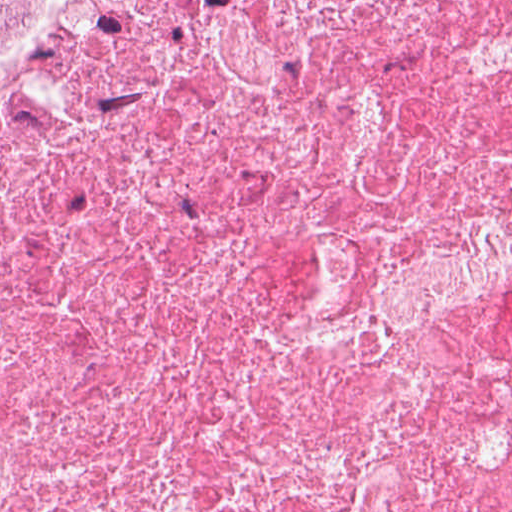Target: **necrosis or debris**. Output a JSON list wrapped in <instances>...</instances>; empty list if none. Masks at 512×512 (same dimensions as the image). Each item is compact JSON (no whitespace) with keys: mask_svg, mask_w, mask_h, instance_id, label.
Returning a JSON list of instances; mask_svg holds the SVG:
<instances>
[{"mask_svg":"<svg viewBox=\"0 0 512 512\" xmlns=\"http://www.w3.org/2000/svg\"><path fill=\"white\" fill-rule=\"evenodd\" d=\"M0 512H512V0L0 53Z\"/></svg>","mask_w":512,"mask_h":512,"instance_id":"1","label":"necrosis or debris"}]
</instances>
